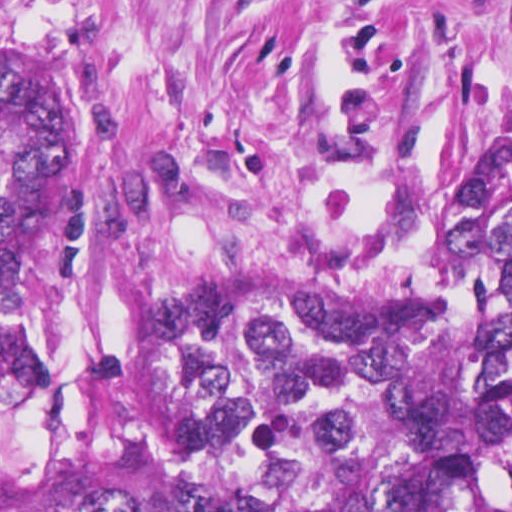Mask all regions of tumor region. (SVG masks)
<instances>
[{"instance_id": "obj_1", "label": "tumor region", "mask_w": 512, "mask_h": 512, "mask_svg": "<svg viewBox=\"0 0 512 512\" xmlns=\"http://www.w3.org/2000/svg\"><path fill=\"white\" fill-rule=\"evenodd\" d=\"M79 111L0 60V512H512V195L436 280L85 245Z\"/></svg>"}]
</instances>
